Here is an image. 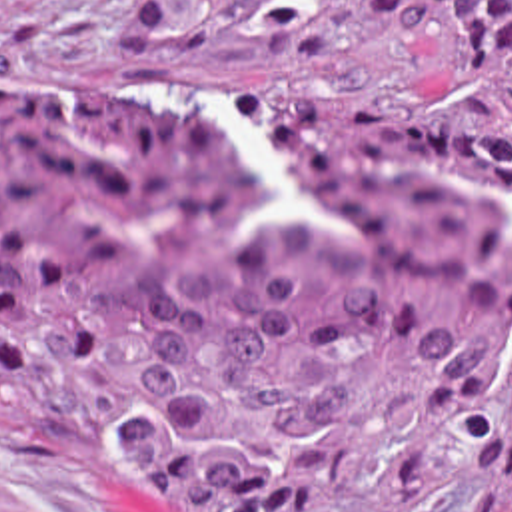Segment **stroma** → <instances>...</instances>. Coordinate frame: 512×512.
<instances>
[{
  "label": "stroma",
  "mask_w": 512,
  "mask_h": 512,
  "mask_svg": "<svg viewBox=\"0 0 512 512\" xmlns=\"http://www.w3.org/2000/svg\"><path fill=\"white\" fill-rule=\"evenodd\" d=\"M0 79H120L298 109L448 117L466 89L454 13L402 37L380 19L280 25V0H0ZM464 485L420 512H494ZM0 512H142L110 445L0 439Z\"/></svg>",
  "instance_id": "stroma-1"
}]
</instances>
